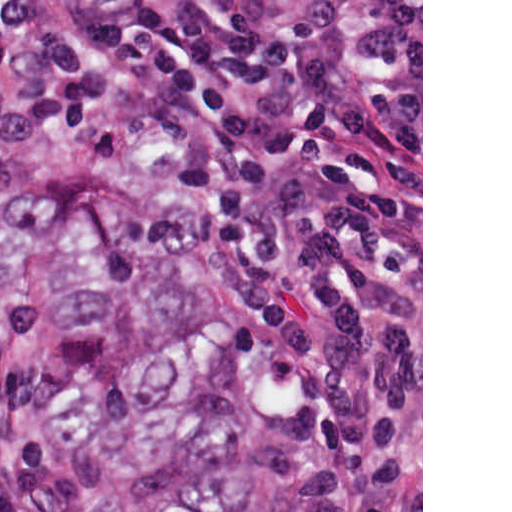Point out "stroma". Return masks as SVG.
I'll use <instances>...</instances> for the list:
<instances>
[{
    "instance_id": "1",
    "label": "stroma",
    "mask_w": 512,
    "mask_h": 512,
    "mask_svg": "<svg viewBox=\"0 0 512 512\" xmlns=\"http://www.w3.org/2000/svg\"><path fill=\"white\" fill-rule=\"evenodd\" d=\"M97 125L0 147V170L84 150ZM0 421L75 512H294L308 390L224 210L139 168L50 184L1 215Z\"/></svg>"
}]
</instances>
